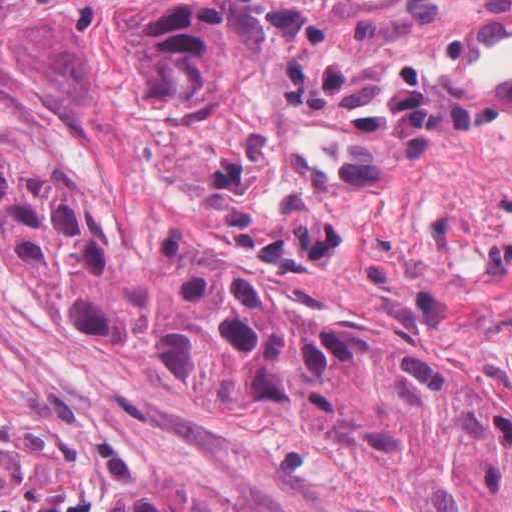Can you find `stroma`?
<instances>
[{
  "label": "stroma",
  "mask_w": 512,
  "mask_h": 512,
  "mask_svg": "<svg viewBox=\"0 0 512 512\" xmlns=\"http://www.w3.org/2000/svg\"><path fill=\"white\" fill-rule=\"evenodd\" d=\"M0 512H64L1 401Z\"/></svg>",
  "instance_id": "stroma-1"
}]
</instances>
